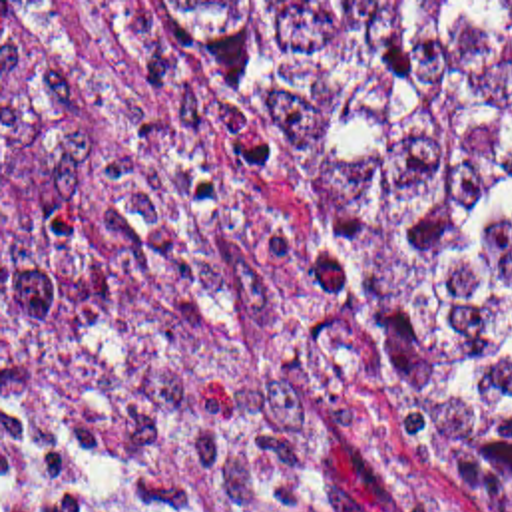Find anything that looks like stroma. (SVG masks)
Returning <instances> with one entry per match:
<instances>
[{
  "mask_svg": "<svg viewBox=\"0 0 512 512\" xmlns=\"http://www.w3.org/2000/svg\"><path fill=\"white\" fill-rule=\"evenodd\" d=\"M2 2H74L102 60L199 153L237 213L297 281L299 345L347 416L370 470V512H490L454 464L394 410L358 335L335 239L265 129L247 118L163 2L512 0H0V512L2 484H28L80 512H253L165 462L62 436L2 412Z\"/></svg>",
  "mask_w": 512,
  "mask_h": 512,
  "instance_id": "35a3bbf8",
  "label": "stroma"
}]
</instances>
